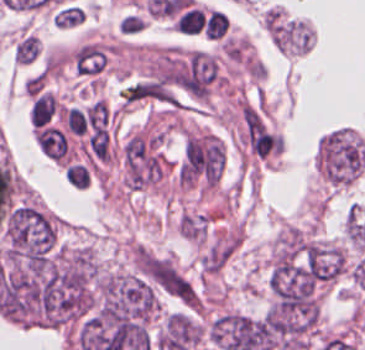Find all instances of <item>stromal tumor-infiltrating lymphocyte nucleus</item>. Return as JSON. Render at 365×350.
Instances as JSON below:
<instances>
[{
  "instance_id": "1",
  "label": "stromal tumor-infiltrating lymphocyte nucleus",
  "mask_w": 365,
  "mask_h": 350,
  "mask_svg": "<svg viewBox=\"0 0 365 350\" xmlns=\"http://www.w3.org/2000/svg\"><path fill=\"white\" fill-rule=\"evenodd\" d=\"M36 141L46 157L61 161L65 156L66 142L60 129L43 126L36 132Z\"/></svg>"
},
{
  "instance_id": "2",
  "label": "stromal tumor-infiltrating lymphocyte nucleus",
  "mask_w": 365,
  "mask_h": 350,
  "mask_svg": "<svg viewBox=\"0 0 365 350\" xmlns=\"http://www.w3.org/2000/svg\"><path fill=\"white\" fill-rule=\"evenodd\" d=\"M64 177L75 190H88L93 182V171L84 161L72 160L65 168Z\"/></svg>"
}]
</instances>
